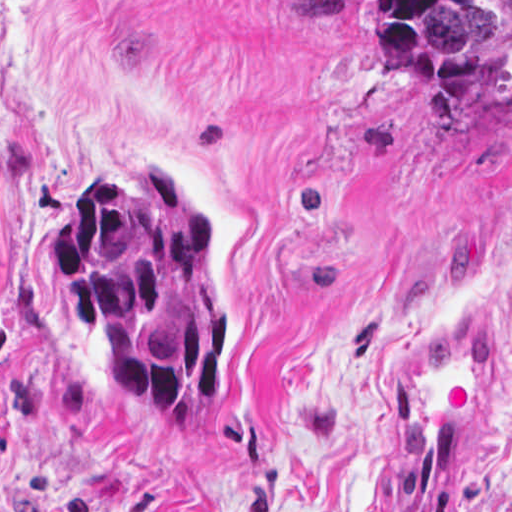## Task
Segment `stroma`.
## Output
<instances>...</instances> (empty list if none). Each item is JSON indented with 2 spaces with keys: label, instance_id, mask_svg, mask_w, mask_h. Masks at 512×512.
Returning <instances> with one entry per match:
<instances>
[{
  "label": "stroma",
  "instance_id": "35a3bbf8",
  "mask_svg": "<svg viewBox=\"0 0 512 512\" xmlns=\"http://www.w3.org/2000/svg\"><path fill=\"white\" fill-rule=\"evenodd\" d=\"M138 165L213 238L197 426L110 390L45 266ZM473 317L500 376L458 512H512V96L447 114L370 21L269 0H0V512H374L398 386Z\"/></svg>",
  "mask_w": 512,
  "mask_h": 512
}]
</instances>
